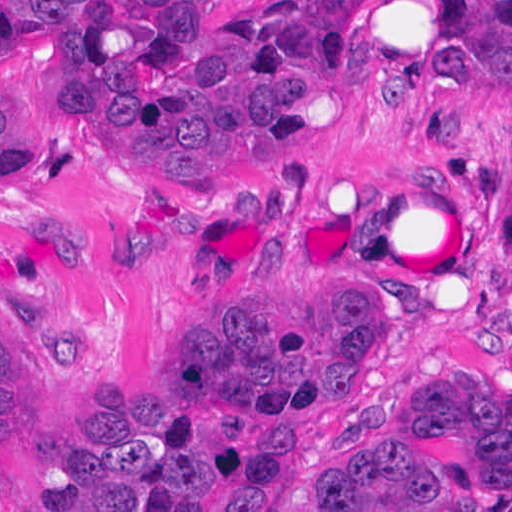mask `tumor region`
I'll return each instance as SVG.
<instances>
[{
	"label": "tumor region",
	"instance_id": "tumor-region-1",
	"mask_svg": "<svg viewBox=\"0 0 512 512\" xmlns=\"http://www.w3.org/2000/svg\"><path fill=\"white\" fill-rule=\"evenodd\" d=\"M368 0H277L229 31H199L193 0H0V34L49 49L85 125L142 172L136 191H218L267 164L347 77ZM455 63L512 83V0H447ZM400 112L413 95L386 86ZM37 135L0 99V189L42 172ZM62 271L93 258V229L49 239ZM507 244L512 253V200ZM182 361L106 385L95 450L62 499L33 512H245L331 414L375 389L386 304L204 298ZM54 433L48 374L0 285V464L29 462ZM512 505V402L435 376L334 442L313 491L287 512H404Z\"/></svg>",
	"mask_w": 512,
	"mask_h": 512
}]
</instances>
